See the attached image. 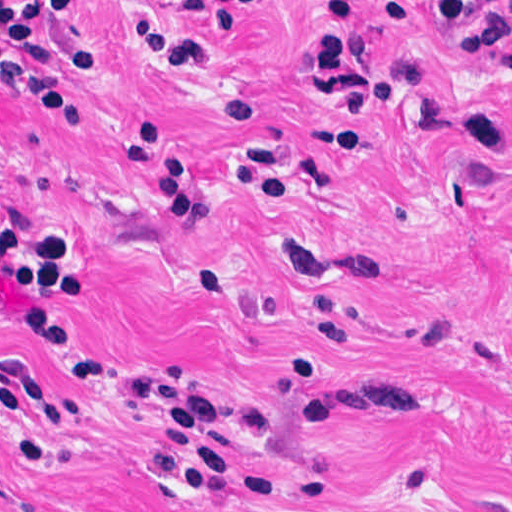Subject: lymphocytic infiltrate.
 I'll return each mask as SVG.
<instances>
[{
  "instance_id": "lymphocytic-infiltrate-1",
  "label": "lymphocytic infiltrate",
  "mask_w": 512,
  "mask_h": 512,
  "mask_svg": "<svg viewBox=\"0 0 512 512\" xmlns=\"http://www.w3.org/2000/svg\"><path fill=\"white\" fill-rule=\"evenodd\" d=\"M156 0H138L132 32L149 30ZM272 0L211 3L214 35L235 39L247 20ZM443 34L458 41L473 61L491 63L512 50V0H424ZM83 0H0V80L25 96L35 109L73 129L78 136L91 120L72 82L60 70L102 64V22L85 11ZM311 68L332 108L345 117L322 125L320 146L329 154H349L365 138L379 107L360 66L356 1L328 0L314 20ZM79 249H44L0 226V276L19 288L21 306L0 303V324L23 329L55 350L67 375L97 380L101 355L60 309L66 296L80 298ZM226 268L205 261L196 283L216 288ZM332 310L312 303L309 331L294 360L279 373L277 388L303 386L327 360L324 339L340 347L352 328L331 319ZM415 371L387 383H367L305 401L303 421L336 416H394L410 421ZM129 395L144 407L151 452L141 465L206 492L236 510L287 501L272 498L270 481L250 456L265 441L266 416L238 402L218 400L176 377L145 374L131 378ZM79 408L49 395L29 370L0 376V416L43 429L77 416Z\"/></svg>"
}]
</instances>
